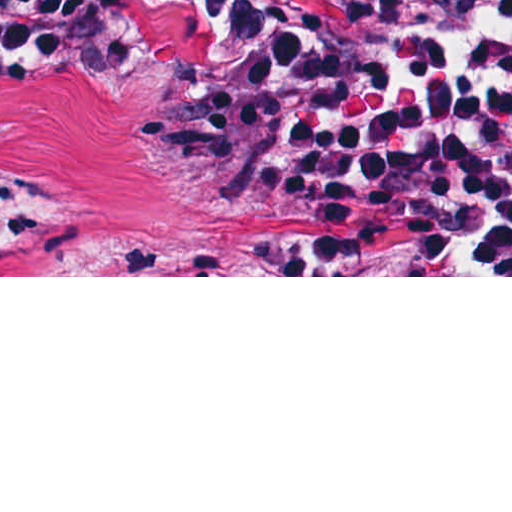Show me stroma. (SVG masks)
<instances>
[{"label": "stroma", "instance_id": "obj_1", "mask_svg": "<svg viewBox=\"0 0 512 512\" xmlns=\"http://www.w3.org/2000/svg\"><path fill=\"white\" fill-rule=\"evenodd\" d=\"M130 55L266 72L249 51L196 25H155ZM157 221L210 236L227 275H0V277H512V275H350L284 242L227 229Z\"/></svg>", "mask_w": 512, "mask_h": 512}]
</instances>
